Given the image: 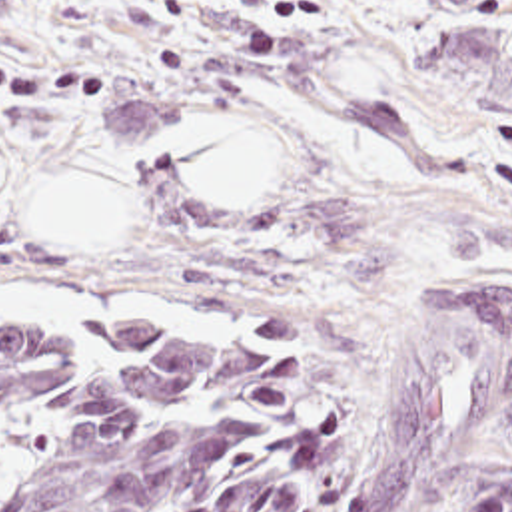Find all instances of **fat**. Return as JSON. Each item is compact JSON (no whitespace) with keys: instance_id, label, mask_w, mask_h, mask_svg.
<instances>
[{"instance_id":"fat-1","label":"fat","mask_w":512,"mask_h":512,"mask_svg":"<svg viewBox=\"0 0 512 512\" xmlns=\"http://www.w3.org/2000/svg\"><path fill=\"white\" fill-rule=\"evenodd\" d=\"M169 161L179 187L203 209H245L265 201L275 151L243 121L201 119L173 131ZM1 189L0 159V195ZM127 221L123 187L99 169L55 181L27 215L31 239H73L79 247H119Z\"/></svg>"}]
</instances>
